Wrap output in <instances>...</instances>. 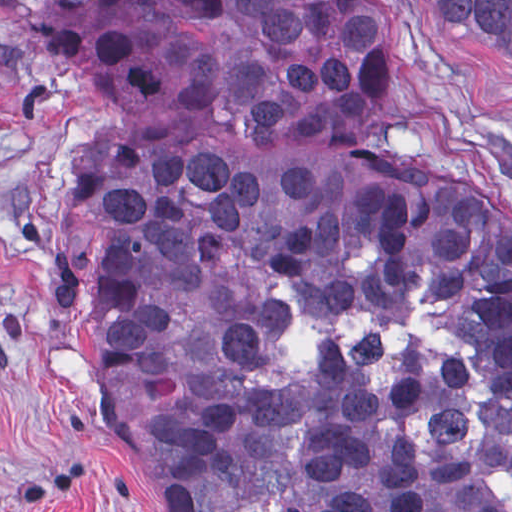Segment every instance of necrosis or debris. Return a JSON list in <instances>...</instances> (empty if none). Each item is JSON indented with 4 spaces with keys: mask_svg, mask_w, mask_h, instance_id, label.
Listing matches in <instances>:
<instances>
[{
    "mask_svg": "<svg viewBox=\"0 0 512 512\" xmlns=\"http://www.w3.org/2000/svg\"><path fill=\"white\" fill-rule=\"evenodd\" d=\"M291 325L273 344L274 370L262 386L289 390L313 368L316 357L342 351L349 372L385 389L405 379L425 382L427 410L418 441L433 461H473L486 441L491 383L482 370V348L451 327V313L430 280L411 289L410 310L393 317L367 311L322 315L308 297L285 287Z\"/></svg>",
    "mask_w": 512,
    "mask_h": 512,
    "instance_id": "1",
    "label": "necrosis or debris"
}]
</instances>
